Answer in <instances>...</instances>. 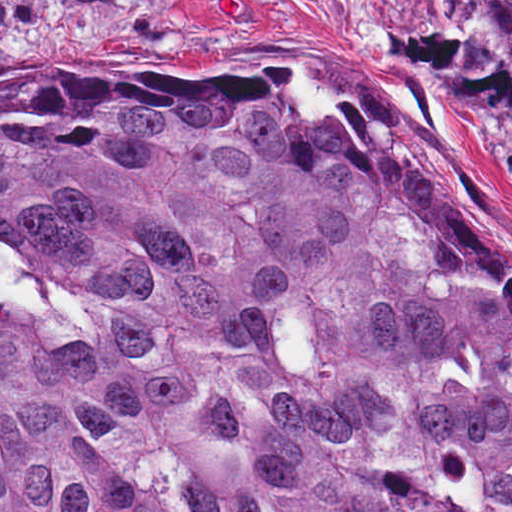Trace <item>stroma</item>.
<instances>
[{
  "mask_svg": "<svg viewBox=\"0 0 512 512\" xmlns=\"http://www.w3.org/2000/svg\"><path fill=\"white\" fill-rule=\"evenodd\" d=\"M434 1L512 0H0V74L68 60L292 70L293 90L348 111L448 190L512 264V103H458L394 54L370 12L432 15Z\"/></svg>",
  "mask_w": 512,
  "mask_h": 512,
  "instance_id": "1",
  "label": "stroma"
}]
</instances>
